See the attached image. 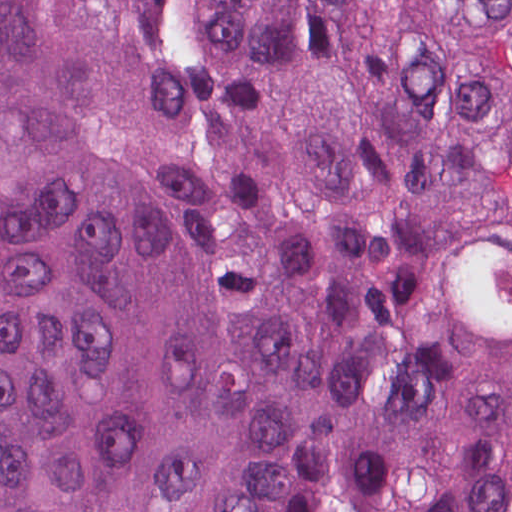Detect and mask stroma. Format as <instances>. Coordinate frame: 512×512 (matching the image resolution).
Listing matches in <instances>:
<instances>
[{
	"mask_svg": "<svg viewBox=\"0 0 512 512\" xmlns=\"http://www.w3.org/2000/svg\"><path fill=\"white\" fill-rule=\"evenodd\" d=\"M366 487H343L344 512H350L356 500Z\"/></svg>",
	"mask_w": 512,
	"mask_h": 512,
	"instance_id": "1",
	"label": "stroma"
}]
</instances>
